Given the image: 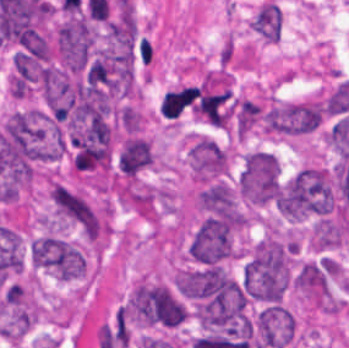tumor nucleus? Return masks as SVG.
Masks as SVG:
<instances>
[{"instance_id":"2f306a5c","label":"tumor nucleus","mask_w":349,"mask_h":348,"mask_svg":"<svg viewBox=\"0 0 349 348\" xmlns=\"http://www.w3.org/2000/svg\"><path fill=\"white\" fill-rule=\"evenodd\" d=\"M128 313L137 325L175 328L182 324L187 306L176 290L144 279L129 293Z\"/></svg>"},{"instance_id":"8643909e","label":"tumor nucleus","mask_w":349,"mask_h":348,"mask_svg":"<svg viewBox=\"0 0 349 348\" xmlns=\"http://www.w3.org/2000/svg\"><path fill=\"white\" fill-rule=\"evenodd\" d=\"M194 206L201 220L238 230L246 226L240 195L226 180L202 182Z\"/></svg>"},{"instance_id":"5ab6c2c4","label":"tumor nucleus","mask_w":349,"mask_h":348,"mask_svg":"<svg viewBox=\"0 0 349 348\" xmlns=\"http://www.w3.org/2000/svg\"><path fill=\"white\" fill-rule=\"evenodd\" d=\"M54 217L85 237H98V216L90 203L59 180L49 183Z\"/></svg>"},{"instance_id":"2cbd58db","label":"tumor nucleus","mask_w":349,"mask_h":348,"mask_svg":"<svg viewBox=\"0 0 349 348\" xmlns=\"http://www.w3.org/2000/svg\"><path fill=\"white\" fill-rule=\"evenodd\" d=\"M188 254L194 262L211 266L232 258V229L211 218L204 220L189 242Z\"/></svg>"},{"instance_id":"3d1891a8","label":"tumor nucleus","mask_w":349,"mask_h":348,"mask_svg":"<svg viewBox=\"0 0 349 348\" xmlns=\"http://www.w3.org/2000/svg\"><path fill=\"white\" fill-rule=\"evenodd\" d=\"M188 167L199 181L218 180L228 173L227 150L207 137H200L188 152Z\"/></svg>"},{"instance_id":"2083b535","label":"tumor nucleus","mask_w":349,"mask_h":348,"mask_svg":"<svg viewBox=\"0 0 349 348\" xmlns=\"http://www.w3.org/2000/svg\"><path fill=\"white\" fill-rule=\"evenodd\" d=\"M151 163L149 141L136 136L123 139L116 157V169L119 172L132 177Z\"/></svg>"},{"instance_id":"8087334f","label":"tumor nucleus","mask_w":349,"mask_h":348,"mask_svg":"<svg viewBox=\"0 0 349 348\" xmlns=\"http://www.w3.org/2000/svg\"><path fill=\"white\" fill-rule=\"evenodd\" d=\"M239 176L244 182H278L280 173L275 155L256 150L248 153Z\"/></svg>"},{"instance_id":"c2bd9aea","label":"tumor nucleus","mask_w":349,"mask_h":348,"mask_svg":"<svg viewBox=\"0 0 349 348\" xmlns=\"http://www.w3.org/2000/svg\"><path fill=\"white\" fill-rule=\"evenodd\" d=\"M249 27L263 41L277 42L281 33V10L277 3L265 1L252 16Z\"/></svg>"}]
</instances>
